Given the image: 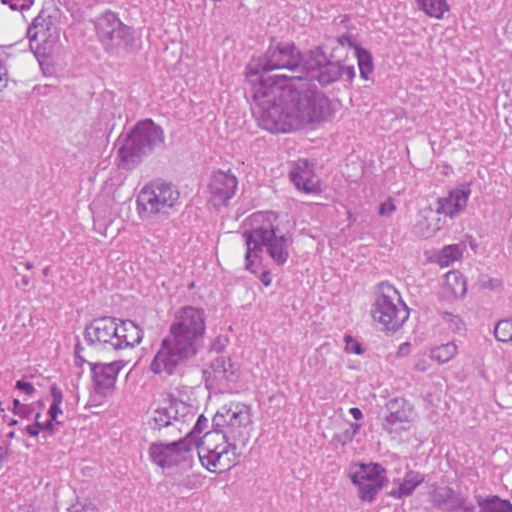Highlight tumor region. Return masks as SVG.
Returning <instances> with one entry per match:
<instances>
[{
  "label": "tumor region",
  "instance_id": "1",
  "mask_svg": "<svg viewBox=\"0 0 512 512\" xmlns=\"http://www.w3.org/2000/svg\"><path fill=\"white\" fill-rule=\"evenodd\" d=\"M144 19L107 0H0V114L35 103L30 15L80 6L140 99L108 126V186L78 214L94 292L77 320L0 371V506L115 512V488L202 499L270 435V373L225 292H167L150 225L203 209V257L251 282L285 211L329 205L333 161H293L254 204L242 165L176 115L188 31L216 6ZM379 39L339 23L273 26L234 55L239 122L265 146H309L367 87L388 96L441 180L419 216L431 274L387 270L348 322L367 385L324 389L304 430L364 512H512V0H403Z\"/></svg>",
  "mask_w": 512,
  "mask_h": 512
}]
</instances>
